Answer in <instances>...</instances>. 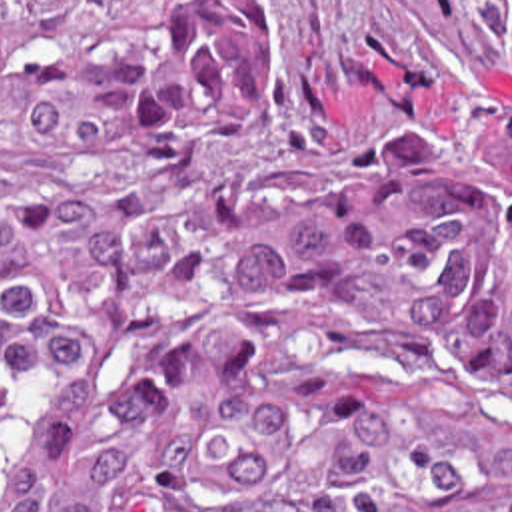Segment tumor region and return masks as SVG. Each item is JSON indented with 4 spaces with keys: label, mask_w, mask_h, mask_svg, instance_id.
<instances>
[{
    "label": "tumor region",
    "mask_w": 512,
    "mask_h": 512,
    "mask_svg": "<svg viewBox=\"0 0 512 512\" xmlns=\"http://www.w3.org/2000/svg\"><path fill=\"white\" fill-rule=\"evenodd\" d=\"M314 176L268 0H0V512H512V118Z\"/></svg>",
    "instance_id": "1"
}]
</instances>
